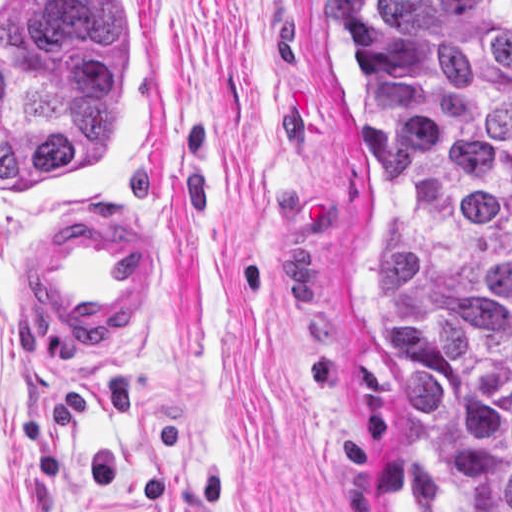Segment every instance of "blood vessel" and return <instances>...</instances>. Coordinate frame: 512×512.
Here are the masks:
<instances>
[{
    "mask_svg": "<svg viewBox=\"0 0 512 512\" xmlns=\"http://www.w3.org/2000/svg\"><path fill=\"white\" fill-rule=\"evenodd\" d=\"M162 265L161 233L119 221H80L49 249L45 291L72 324L117 333L148 304Z\"/></svg>",
    "mask_w": 512,
    "mask_h": 512,
    "instance_id": "8fb6f2fc",
    "label": "blood vessel"
}]
</instances>
